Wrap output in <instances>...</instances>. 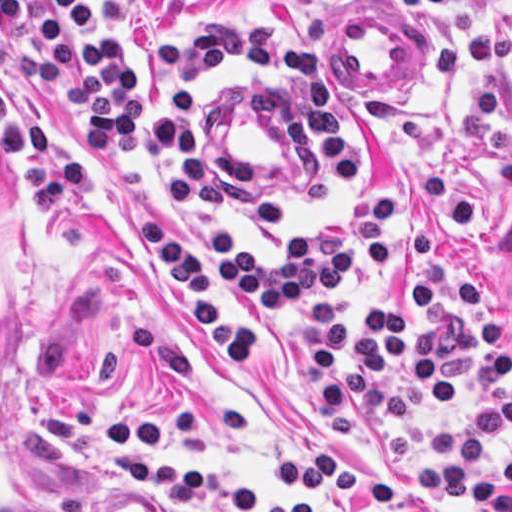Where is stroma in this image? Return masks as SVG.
Here are the masks:
<instances>
[{
  "mask_svg": "<svg viewBox=\"0 0 512 512\" xmlns=\"http://www.w3.org/2000/svg\"><path fill=\"white\" fill-rule=\"evenodd\" d=\"M512 43V1L468 3ZM128 42L150 53L171 31L232 18L256 21L278 39L305 47L361 136L362 179L346 197L317 200L302 187L299 88L232 65L200 68L192 88V135L220 163L228 195L207 212H188L165 146L134 156H90L75 135V99L43 93L30 110L43 136L93 166V176L58 216H36L10 151L0 141V192L24 251L20 344L25 404L56 489L71 512H161L139 483L118 474L120 459L151 466L182 463L200 476L278 497L270 452L237 446L211 453H165L110 429L122 414L177 400L184 419L227 411L255 420L263 440L286 451L289 428L328 443L340 470H362L429 506L479 512L472 499H447L417 485V443L434 427L471 419L463 401H438L385 429L357 407L321 415L303 374V316L260 378L272 400L263 414L206 348L172 277L141 246L142 218L160 237L211 249L236 225L254 254H288L310 226L368 198H396V247L411 232L437 235L441 260L470 274L501 310L512 341V193L495 189L493 166L512 128V58L487 62L456 82H440L435 51L467 35L459 8L401 13L394 0H342L317 13L293 0H123ZM418 30V68L404 88H357L339 65L342 17L375 15ZM184 45H187L185 41ZM333 512H374L355 498Z\"/></svg>",
  "mask_w": 512,
  "mask_h": 512,
  "instance_id": "stroma-1",
  "label": "stroma"
}]
</instances>
